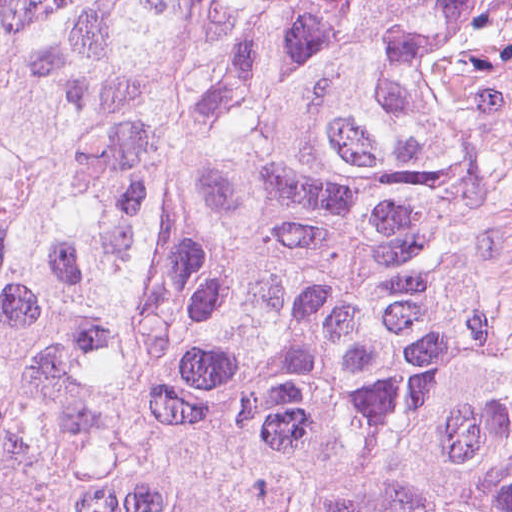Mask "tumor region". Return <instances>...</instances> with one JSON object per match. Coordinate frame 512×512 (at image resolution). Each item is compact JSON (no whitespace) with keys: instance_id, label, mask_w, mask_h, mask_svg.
<instances>
[{"instance_id":"e687c5a6","label":"tumor region","mask_w":512,"mask_h":512,"mask_svg":"<svg viewBox=\"0 0 512 512\" xmlns=\"http://www.w3.org/2000/svg\"><path fill=\"white\" fill-rule=\"evenodd\" d=\"M0 512H512V0H0Z\"/></svg>"}]
</instances>
